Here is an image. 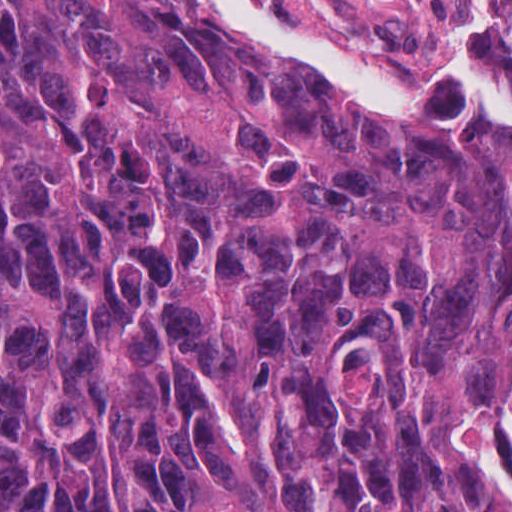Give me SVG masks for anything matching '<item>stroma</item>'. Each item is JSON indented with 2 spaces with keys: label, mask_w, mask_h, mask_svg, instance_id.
<instances>
[{
  "label": "stroma",
  "mask_w": 512,
  "mask_h": 512,
  "mask_svg": "<svg viewBox=\"0 0 512 512\" xmlns=\"http://www.w3.org/2000/svg\"><path fill=\"white\" fill-rule=\"evenodd\" d=\"M304 41L381 69L434 74L454 54L460 23L475 0H244ZM246 43L323 82L286 59ZM331 83V82H329ZM445 90L405 98H371L394 110L424 106ZM512 411L501 422L477 473L490 491L493 512L505 508L492 465Z\"/></svg>",
  "instance_id": "1"
}]
</instances>
